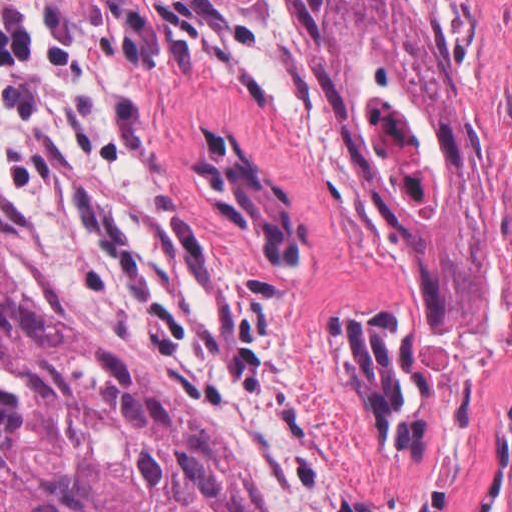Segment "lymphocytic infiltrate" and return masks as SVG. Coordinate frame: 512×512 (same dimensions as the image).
Returning <instances> with one entry per match:
<instances>
[{"mask_svg":"<svg viewBox=\"0 0 512 512\" xmlns=\"http://www.w3.org/2000/svg\"><path fill=\"white\" fill-rule=\"evenodd\" d=\"M57 0H0V86L31 64L35 43L51 33ZM19 172L15 123L0 117V174Z\"/></svg>","mask_w":512,"mask_h":512,"instance_id":"1","label":"lymphocytic infiltrate"}]
</instances>
